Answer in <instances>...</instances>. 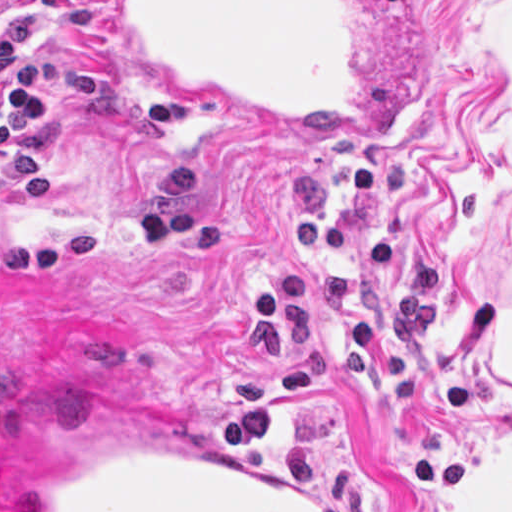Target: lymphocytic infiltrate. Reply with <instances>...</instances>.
Wrapping results in <instances>:
<instances>
[{
    "mask_svg": "<svg viewBox=\"0 0 512 512\" xmlns=\"http://www.w3.org/2000/svg\"><path fill=\"white\" fill-rule=\"evenodd\" d=\"M17 2L0 0V12ZM39 38L30 18L0 25V177L20 201L47 198L53 189L49 161L34 146L50 140L54 118L36 97H74L117 127L163 132L186 123V100L166 94L139 103L88 64L6 61L27 53Z\"/></svg>",
    "mask_w": 512,
    "mask_h": 512,
    "instance_id": "obj_1",
    "label": "lymphocytic infiltrate"
}]
</instances>
